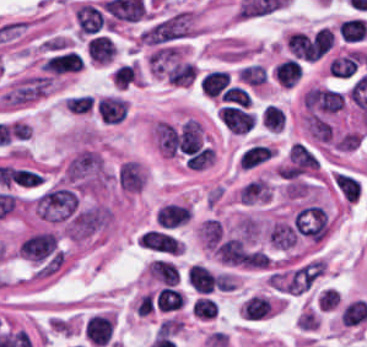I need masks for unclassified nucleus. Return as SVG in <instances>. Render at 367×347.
I'll use <instances>...</instances> for the list:
<instances>
[{
  "mask_svg": "<svg viewBox=\"0 0 367 347\" xmlns=\"http://www.w3.org/2000/svg\"><path fill=\"white\" fill-rule=\"evenodd\" d=\"M240 204H258L272 198V186L267 179L255 177L245 182L236 193Z\"/></svg>",
  "mask_w": 367,
  "mask_h": 347,
  "instance_id": "0b8be0a9",
  "label": "unclassified nucleus"
},
{
  "mask_svg": "<svg viewBox=\"0 0 367 347\" xmlns=\"http://www.w3.org/2000/svg\"><path fill=\"white\" fill-rule=\"evenodd\" d=\"M274 153L275 150L258 142L243 150L238 164L242 170H256L273 160Z\"/></svg>",
  "mask_w": 367,
  "mask_h": 347,
  "instance_id": "b2318f4d",
  "label": "unclassified nucleus"
},
{
  "mask_svg": "<svg viewBox=\"0 0 367 347\" xmlns=\"http://www.w3.org/2000/svg\"><path fill=\"white\" fill-rule=\"evenodd\" d=\"M332 182L347 203H355L361 196V184L354 174L339 171L335 173Z\"/></svg>",
  "mask_w": 367,
  "mask_h": 347,
  "instance_id": "928a53df",
  "label": "unclassified nucleus"
},
{
  "mask_svg": "<svg viewBox=\"0 0 367 347\" xmlns=\"http://www.w3.org/2000/svg\"><path fill=\"white\" fill-rule=\"evenodd\" d=\"M305 124L309 135L321 142L329 141L332 134V127L322 116L308 111Z\"/></svg>",
  "mask_w": 367,
  "mask_h": 347,
  "instance_id": "975e440c",
  "label": "unclassified nucleus"
}]
</instances>
